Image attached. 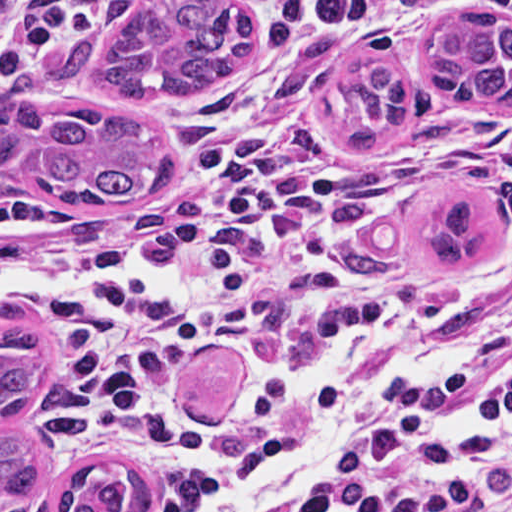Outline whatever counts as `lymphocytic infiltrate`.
<instances>
[{"instance_id": "obj_1", "label": "lymphocytic infiltrate", "mask_w": 512, "mask_h": 512, "mask_svg": "<svg viewBox=\"0 0 512 512\" xmlns=\"http://www.w3.org/2000/svg\"><path fill=\"white\" fill-rule=\"evenodd\" d=\"M65 0L0 32V84L94 26ZM512 0H287L236 70L195 158L198 191L149 233L109 209L0 193V302L57 350L45 439L63 471L105 456L149 466L192 511L293 442L334 376H277L256 411L191 431L162 422L181 377L221 336L358 315L375 287L349 190L369 169L306 132L316 68L354 44ZM293 512H512V282L332 451Z\"/></svg>"}]
</instances>
